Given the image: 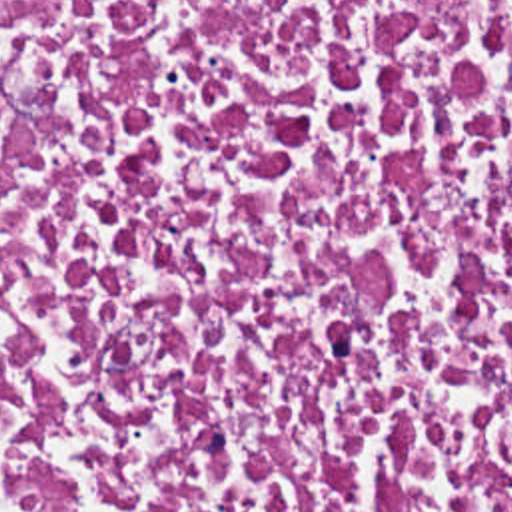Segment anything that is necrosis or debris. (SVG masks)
Listing matches in <instances>:
<instances>
[{
  "label": "necrosis or debris",
  "mask_w": 512,
  "mask_h": 512,
  "mask_svg": "<svg viewBox=\"0 0 512 512\" xmlns=\"http://www.w3.org/2000/svg\"><path fill=\"white\" fill-rule=\"evenodd\" d=\"M0 512H512V0H0Z\"/></svg>",
  "instance_id": "obj_1"
}]
</instances>
